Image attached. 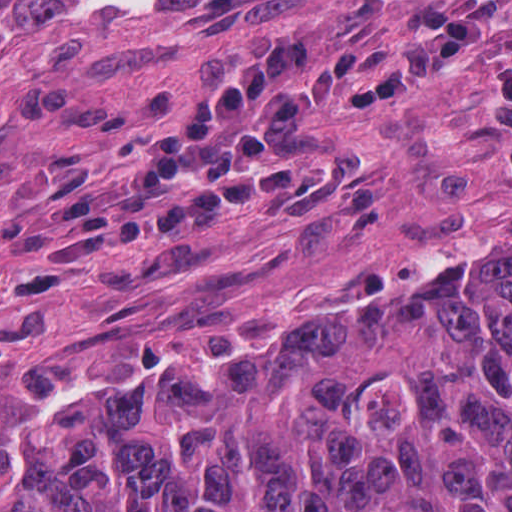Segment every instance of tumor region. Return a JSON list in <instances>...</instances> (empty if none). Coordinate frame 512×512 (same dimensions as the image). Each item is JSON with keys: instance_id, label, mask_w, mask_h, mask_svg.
<instances>
[{"instance_id": "tumor-region-1", "label": "tumor region", "mask_w": 512, "mask_h": 512, "mask_svg": "<svg viewBox=\"0 0 512 512\" xmlns=\"http://www.w3.org/2000/svg\"><path fill=\"white\" fill-rule=\"evenodd\" d=\"M24 3L0 1V22ZM15 252L75 264L50 224ZM511 499L512 281L423 351L237 380L116 371L0 410V512H509Z\"/></svg>"}]
</instances>
